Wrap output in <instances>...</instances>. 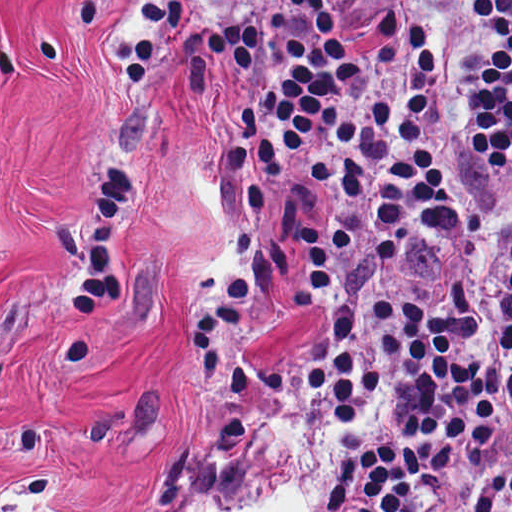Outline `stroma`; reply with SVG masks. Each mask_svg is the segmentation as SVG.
Returning <instances> with one entry per match:
<instances>
[{"instance_id": "stroma-1", "label": "stroma", "mask_w": 512, "mask_h": 512, "mask_svg": "<svg viewBox=\"0 0 512 512\" xmlns=\"http://www.w3.org/2000/svg\"><path fill=\"white\" fill-rule=\"evenodd\" d=\"M259 71L196 58L173 0H0V512L257 504L292 473L272 416L350 442L294 389L315 313L240 320L202 412L182 353L245 209L224 181Z\"/></svg>"}]
</instances>
